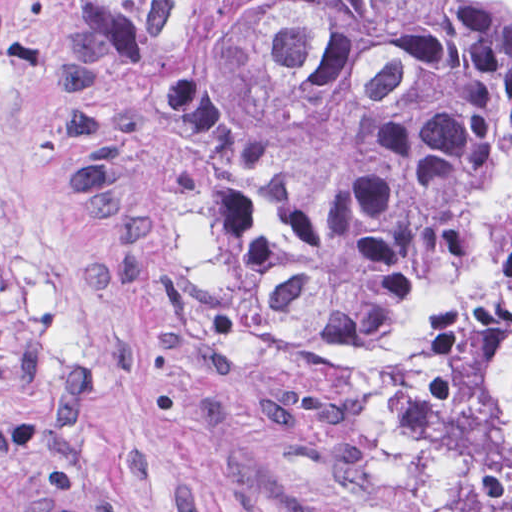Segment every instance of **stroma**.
I'll return each mask as SVG.
<instances>
[{
    "instance_id": "1",
    "label": "stroma",
    "mask_w": 512,
    "mask_h": 512,
    "mask_svg": "<svg viewBox=\"0 0 512 512\" xmlns=\"http://www.w3.org/2000/svg\"><path fill=\"white\" fill-rule=\"evenodd\" d=\"M59 1L0 0V512H423L202 398L97 293L49 147Z\"/></svg>"
}]
</instances>
